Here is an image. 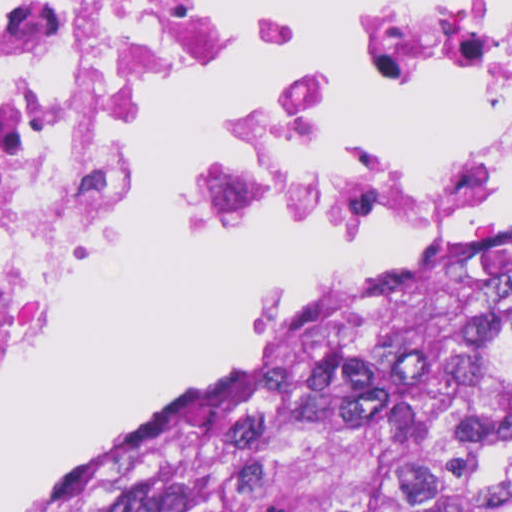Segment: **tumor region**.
Returning <instances> with one entry per match:
<instances>
[{
    "instance_id": "1",
    "label": "tumor region",
    "mask_w": 512,
    "mask_h": 512,
    "mask_svg": "<svg viewBox=\"0 0 512 512\" xmlns=\"http://www.w3.org/2000/svg\"><path fill=\"white\" fill-rule=\"evenodd\" d=\"M38 512H512V221Z\"/></svg>"
}]
</instances>
